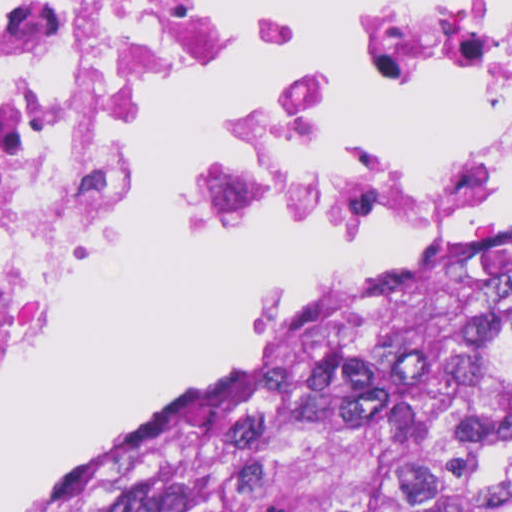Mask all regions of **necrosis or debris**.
I'll return each instance as SVG.
<instances>
[{"instance_id": "obj_1", "label": "necrosis or debris", "mask_w": 512, "mask_h": 512, "mask_svg": "<svg viewBox=\"0 0 512 512\" xmlns=\"http://www.w3.org/2000/svg\"><path fill=\"white\" fill-rule=\"evenodd\" d=\"M238 0H0V375L78 282L177 71ZM315 88L200 189L226 230L465 217L512 166V0H304Z\"/></svg>"}]
</instances>
